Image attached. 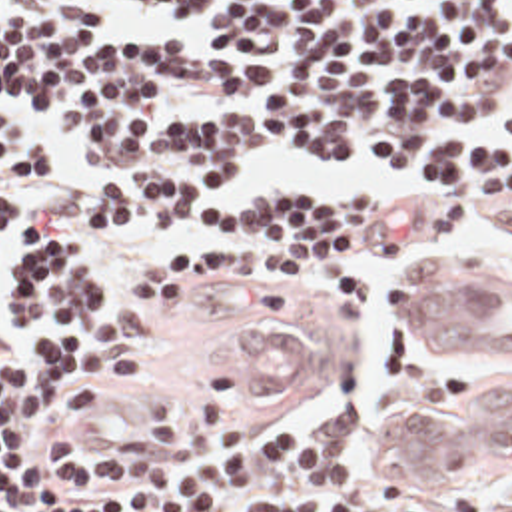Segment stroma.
<instances>
[{
  "mask_svg": "<svg viewBox=\"0 0 512 512\" xmlns=\"http://www.w3.org/2000/svg\"><path fill=\"white\" fill-rule=\"evenodd\" d=\"M510 105L512 89L496 101L482 121L472 125V139L512 156V133L494 121ZM35 113L41 119L47 142L53 146H77L61 133L57 125L45 119L39 111ZM25 148L41 158L45 172L47 164L43 156L27 144ZM255 168L257 164L243 170V174ZM33 186H25L15 192L29 196ZM355 202H376V210L363 230L343 240L339 246V264L343 272L355 280L359 290V296L351 304L303 298L289 290L263 286L237 276H207L171 302V306L159 318L157 342L151 354L141 358L121 378L101 384L105 394L91 410L71 420L41 418L39 428L45 432H61L91 448H119L133 444L141 436V418L137 410L155 402L191 404L207 376L217 370L233 376L245 386L247 414L251 422L303 420L309 428H333L339 418L341 404L327 414L319 408V394L347 368L349 356L357 342L363 302V272L355 264L378 252L422 250L428 240L452 236L456 234V220L460 212L466 210L482 212L500 222L504 228L512 230V208L476 206L462 194L448 188L446 182L444 190L430 200ZM99 226L103 232L111 234L157 232L161 236L159 254L167 252L183 234L193 232L131 228L109 220L101 212ZM13 228L15 224L0 232V256L13 234ZM428 260L430 258L420 254L406 260V274L400 286V308L404 318L412 322L414 280ZM474 262L492 264L496 260ZM496 264H500L498 270L502 272L512 298V266L504 262ZM99 288L113 304H121L129 296V284L115 290H107L103 286ZM247 306H267L273 310L283 308L309 326L315 338V380L301 396H267L243 382L227 364L229 330ZM510 364L512 356H436L422 340H416L410 330H398L390 342L388 390L382 398L380 412L376 416H369V422L402 412L462 408L472 402V398L494 378L498 370ZM365 428L361 430L345 468L351 470L367 488L376 490L380 480L386 478H408L416 484V512H512V466L498 472H484L476 478H418L390 474L376 466L365 454Z\"/></svg>",
  "mask_w": 512,
  "mask_h": 512,
  "instance_id": "35a3bbf8",
  "label": "stroma"
}]
</instances>
